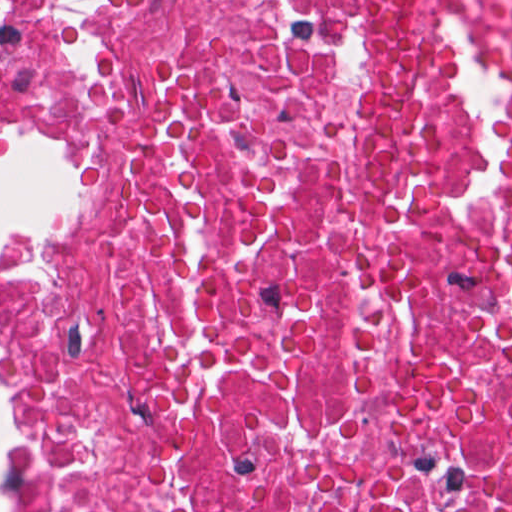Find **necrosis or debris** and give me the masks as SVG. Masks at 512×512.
Here are the masks:
<instances>
[{
    "instance_id": "obj_1",
    "label": "necrosis or debris",
    "mask_w": 512,
    "mask_h": 512,
    "mask_svg": "<svg viewBox=\"0 0 512 512\" xmlns=\"http://www.w3.org/2000/svg\"><path fill=\"white\" fill-rule=\"evenodd\" d=\"M34 111L26 512H512V0H0Z\"/></svg>"
}]
</instances>
